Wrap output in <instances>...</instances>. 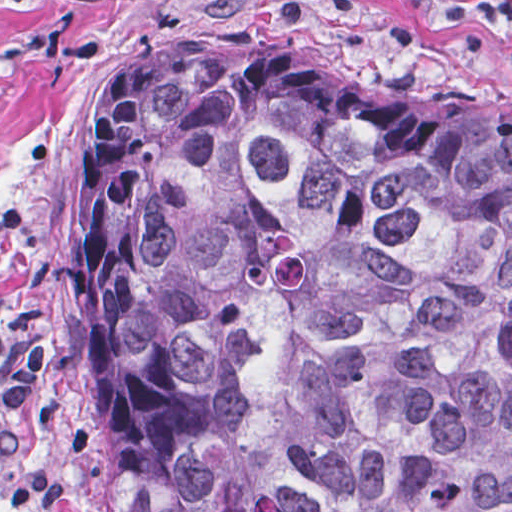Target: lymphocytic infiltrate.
<instances>
[{
  "mask_svg": "<svg viewBox=\"0 0 512 512\" xmlns=\"http://www.w3.org/2000/svg\"><path fill=\"white\" fill-rule=\"evenodd\" d=\"M470 21H512V1H443ZM11 199L1 195V227L17 228ZM39 375V334L25 343L1 345V466L25 441V418ZM62 497V485L34 469L10 488L1 504L46 508Z\"/></svg>",
  "mask_w": 512,
  "mask_h": 512,
  "instance_id": "1",
  "label": "lymphocytic infiltrate"
}]
</instances>
